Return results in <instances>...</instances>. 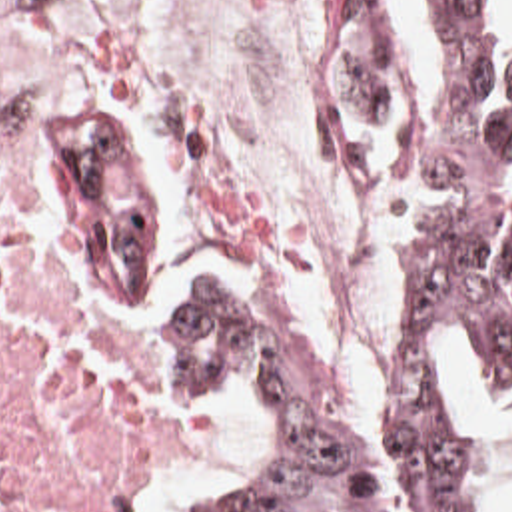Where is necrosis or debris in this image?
Listing matches in <instances>:
<instances>
[{
	"label": "necrosis or debris",
	"mask_w": 512,
	"mask_h": 512,
	"mask_svg": "<svg viewBox=\"0 0 512 512\" xmlns=\"http://www.w3.org/2000/svg\"><path fill=\"white\" fill-rule=\"evenodd\" d=\"M0 112L57 120L91 146L155 252L215 206L207 136L183 90L69 2L0 0ZM187 448L135 338L37 258L19 170L0 164V512H137Z\"/></svg>",
	"instance_id": "obj_1"
}]
</instances>
